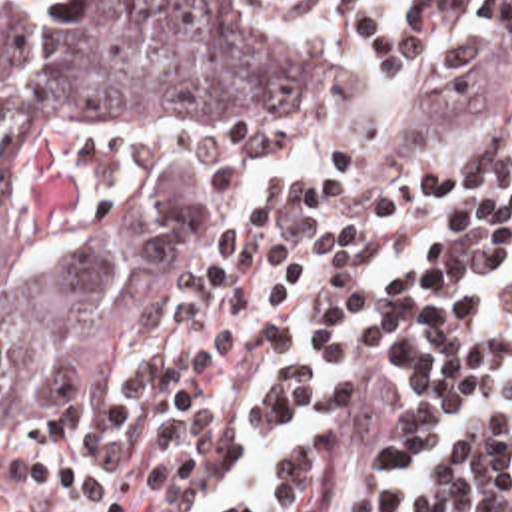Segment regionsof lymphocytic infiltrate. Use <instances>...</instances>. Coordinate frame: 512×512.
Returning <instances> with one entry per match:
<instances>
[{
    "mask_svg": "<svg viewBox=\"0 0 512 512\" xmlns=\"http://www.w3.org/2000/svg\"><path fill=\"white\" fill-rule=\"evenodd\" d=\"M293 1L388 58H414L432 24V0ZM474 10L512 26V0ZM458 46L478 78L466 148L398 198L233 262L159 344L151 388L73 512H187L239 456L237 402L263 358L257 422L321 424L275 460L271 512H512V430L486 426L442 448L416 502L400 496L450 410L512 400V338L474 304L512 256V126L464 0Z\"/></svg>",
    "mask_w": 512,
    "mask_h": 512,
    "instance_id": "1",
    "label": "lymphocytic infiltrate"
}]
</instances>
